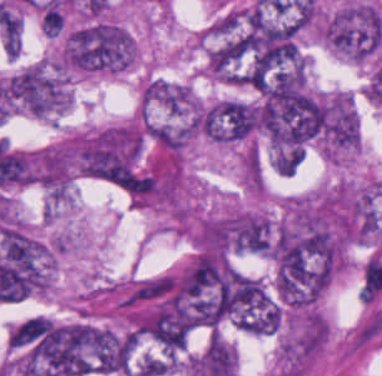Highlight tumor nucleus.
Segmentation results:
<instances>
[{"label": "tumor nucleus", "mask_w": 382, "mask_h": 376, "mask_svg": "<svg viewBox=\"0 0 382 376\" xmlns=\"http://www.w3.org/2000/svg\"><path fill=\"white\" fill-rule=\"evenodd\" d=\"M135 63L134 35L108 9H88L64 30L58 48L69 77L124 73Z\"/></svg>", "instance_id": "obj_1"}, {"label": "tumor nucleus", "mask_w": 382, "mask_h": 376, "mask_svg": "<svg viewBox=\"0 0 382 376\" xmlns=\"http://www.w3.org/2000/svg\"><path fill=\"white\" fill-rule=\"evenodd\" d=\"M70 98L69 76L56 64L37 62L0 82L1 117L55 119Z\"/></svg>", "instance_id": "obj_2"}, {"label": "tumor nucleus", "mask_w": 382, "mask_h": 376, "mask_svg": "<svg viewBox=\"0 0 382 376\" xmlns=\"http://www.w3.org/2000/svg\"><path fill=\"white\" fill-rule=\"evenodd\" d=\"M321 33L333 53L358 63L380 45L381 13L373 3L347 0L321 18Z\"/></svg>", "instance_id": "obj_3"}, {"label": "tumor nucleus", "mask_w": 382, "mask_h": 376, "mask_svg": "<svg viewBox=\"0 0 382 376\" xmlns=\"http://www.w3.org/2000/svg\"><path fill=\"white\" fill-rule=\"evenodd\" d=\"M315 143L326 159L337 162L358 147L357 111L346 89L316 93Z\"/></svg>", "instance_id": "obj_4"}, {"label": "tumor nucleus", "mask_w": 382, "mask_h": 376, "mask_svg": "<svg viewBox=\"0 0 382 376\" xmlns=\"http://www.w3.org/2000/svg\"><path fill=\"white\" fill-rule=\"evenodd\" d=\"M259 101L224 97L201 103L203 134L212 142L232 144L249 139L258 125Z\"/></svg>", "instance_id": "obj_5"}, {"label": "tumor nucleus", "mask_w": 382, "mask_h": 376, "mask_svg": "<svg viewBox=\"0 0 382 376\" xmlns=\"http://www.w3.org/2000/svg\"><path fill=\"white\" fill-rule=\"evenodd\" d=\"M303 157V146H283L271 156V167L279 176H292Z\"/></svg>", "instance_id": "obj_6"}]
</instances>
